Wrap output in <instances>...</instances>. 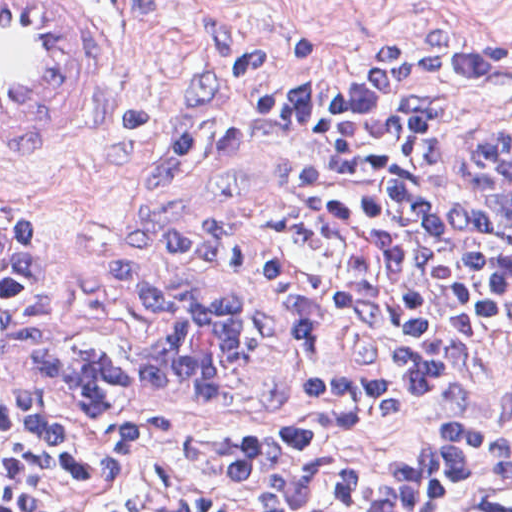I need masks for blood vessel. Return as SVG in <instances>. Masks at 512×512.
<instances>
[{"label": "blood vessel", "mask_w": 512, "mask_h": 512, "mask_svg": "<svg viewBox=\"0 0 512 512\" xmlns=\"http://www.w3.org/2000/svg\"><path fill=\"white\" fill-rule=\"evenodd\" d=\"M101 54L69 0H0V158L78 107Z\"/></svg>", "instance_id": "blood-vessel-1"}]
</instances>
